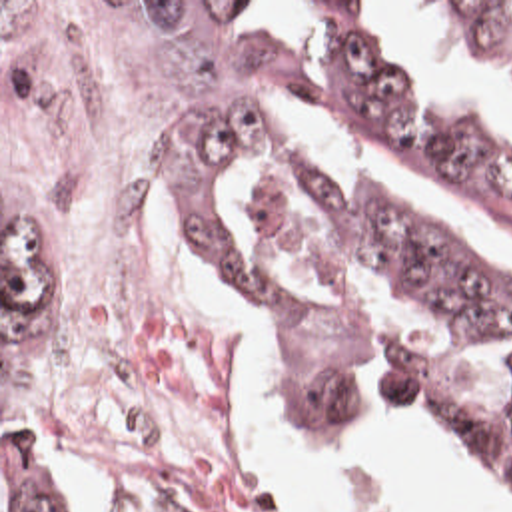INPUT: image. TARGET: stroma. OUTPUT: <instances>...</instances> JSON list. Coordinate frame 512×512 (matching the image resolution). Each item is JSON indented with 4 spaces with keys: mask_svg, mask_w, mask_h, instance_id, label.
<instances>
[{
    "mask_svg": "<svg viewBox=\"0 0 512 512\" xmlns=\"http://www.w3.org/2000/svg\"><path fill=\"white\" fill-rule=\"evenodd\" d=\"M2 2H194L186 26L180 58H178V144L182 118L190 106L194 82L202 62L204 42L224 2L244 0H0V512H2V457L22 467L32 481L46 493L56 512H80L66 479L62 457L66 453L108 461L116 475L138 495V499L154 512H220V505L206 501L128 447L106 443H56L32 417L28 409L24 375L12 349V299L2 274ZM308 2H373V0H308ZM425 2H512V0H425ZM230 309V307H228ZM236 325V393L240 391V375H246L260 389L272 395L286 409L302 419H313L306 405L276 375L270 359L242 327L230 311ZM385 421L397 431L417 437L445 455L479 481L503 491L512 503V485L493 475H485L459 457L441 437L415 427L403 419ZM262 512H310L274 491L260 507Z\"/></svg>",
    "mask_w": 512,
    "mask_h": 512,
    "instance_id": "stroma-1",
    "label": "stroma"
}]
</instances>
